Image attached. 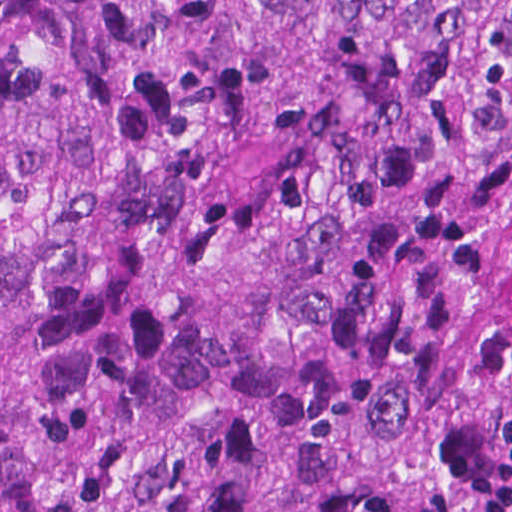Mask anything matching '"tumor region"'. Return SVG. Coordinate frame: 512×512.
<instances>
[{"label":"tumor region","mask_w":512,"mask_h":512,"mask_svg":"<svg viewBox=\"0 0 512 512\" xmlns=\"http://www.w3.org/2000/svg\"><path fill=\"white\" fill-rule=\"evenodd\" d=\"M0 512H512V0H0Z\"/></svg>","instance_id":"e687c5a6"}]
</instances>
